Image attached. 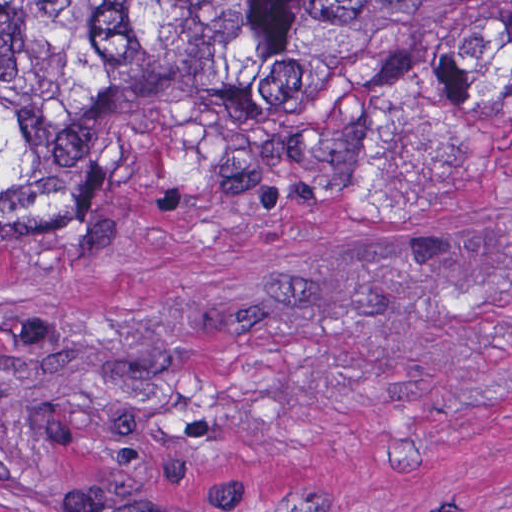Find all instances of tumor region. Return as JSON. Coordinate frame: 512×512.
Masks as SVG:
<instances>
[{"label":"tumor region","instance_id":"tumor-region-1","mask_svg":"<svg viewBox=\"0 0 512 512\" xmlns=\"http://www.w3.org/2000/svg\"><path fill=\"white\" fill-rule=\"evenodd\" d=\"M512 102V0H0V252L119 205L368 203Z\"/></svg>","mask_w":512,"mask_h":512}]
</instances>
